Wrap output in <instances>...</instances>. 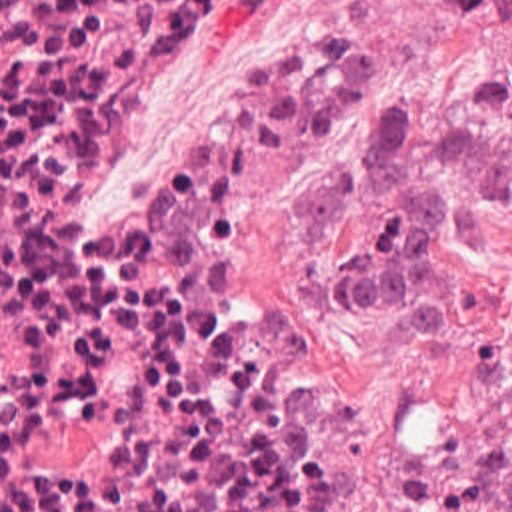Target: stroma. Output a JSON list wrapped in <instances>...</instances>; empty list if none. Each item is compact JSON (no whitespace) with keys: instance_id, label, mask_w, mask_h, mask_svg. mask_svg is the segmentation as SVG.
<instances>
[{"instance_id":"35a3bbf8","label":"stroma","mask_w":512,"mask_h":512,"mask_svg":"<svg viewBox=\"0 0 512 512\" xmlns=\"http://www.w3.org/2000/svg\"><path fill=\"white\" fill-rule=\"evenodd\" d=\"M280 28H334L352 46L356 82L244 189L230 231L224 323L298 365L360 467H396L464 433L486 435L470 512H492L512 451V199L492 247L452 251L456 335L412 345L376 313L336 321L306 305L312 273L368 243L374 209L360 207L350 221L314 233L300 221L296 197L358 143L370 100L386 88L512 137L508 22L492 12L458 14L450 0H198L194 60L156 74L132 96L86 153L70 205L78 219L102 215L204 50Z\"/></svg>"}]
</instances>
